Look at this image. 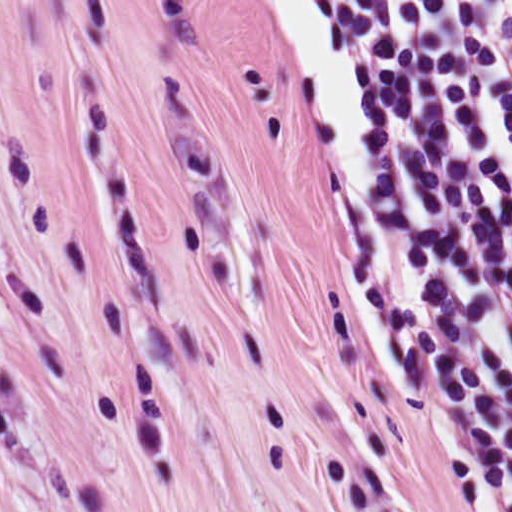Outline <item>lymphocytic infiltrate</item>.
<instances>
[{
    "label": "lymphocytic infiltrate",
    "instance_id": "f902f5d3",
    "mask_svg": "<svg viewBox=\"0 0 512 512\" xmlns=\"http://www.w3.org/2000/svg\"><path fill=\"white\" fill-rule=\"evenodd\" d=\"M368 121L357 315L483 512H512V0H317Z\"/></svg>",
    "mask_w": 512,
    "mask_h": 512
}]
</instances>
